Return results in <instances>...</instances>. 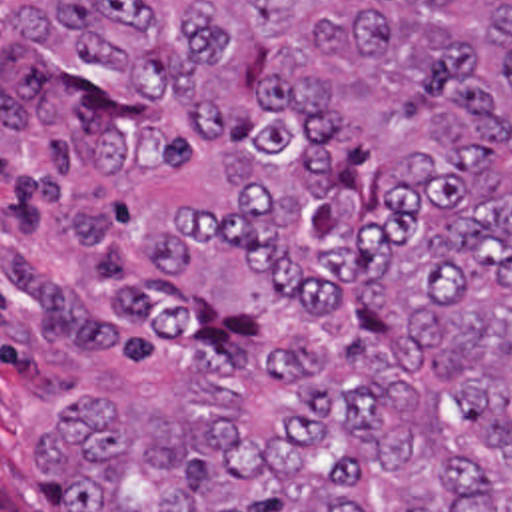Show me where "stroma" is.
Instances as JSON below:
<instances>
[{"instance_id":"1","label":"stroma","mask_w":512,"mask_h":512,"mask_svg":"<svg viewBox=\"0 0 512 512\" xmlns=\"http://www.w3.org/2000/svg\"><path fill=\"white\" fill-rule=\"evenodd\" d=\"M72 251L46 181L0 155V512H68L42 470L36 428L78 392L144 380L128 352L74 330L40 287V271Z\"/></svg>"}]
</instances>
